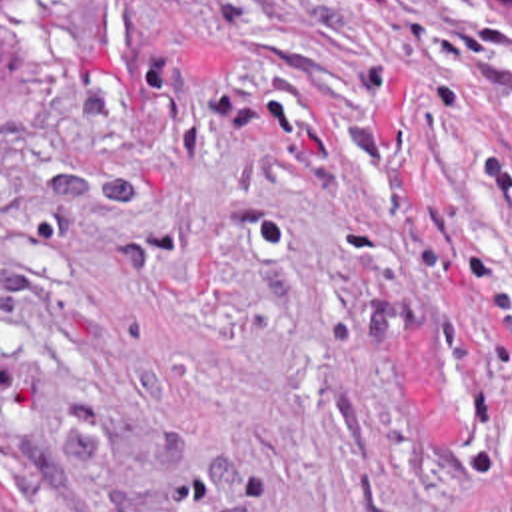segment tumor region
Here are the masks:
<instances>
[{
	"label": "tumor region",
	"instance_id": "obj_1",
	"mask_svg": "<svg viewBox=\"0 0 512 512\" xmlns=\"http://www.w3.org/2000/svg\"><path fill=\"white\" fill-rule=\"evenodd\" d=\"M37 2L39 0H0V16L29 12ZM498 2L506 10V14L512 16V0H498Z\"/></svg>",
	"mask_w": 512,
	"mask_h": 512
}]
</instances>
